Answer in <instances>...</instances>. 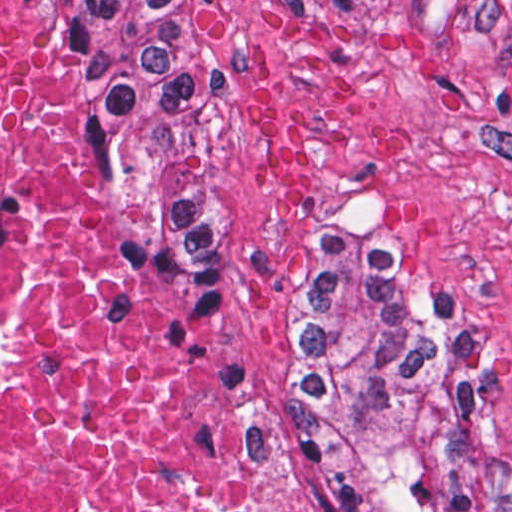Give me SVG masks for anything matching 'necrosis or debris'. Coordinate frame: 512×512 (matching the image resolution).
<instances>
[{
  "label": "necrosis or debris",
  "instance_id": "4bbe7bcc",
  "mask_svg": "<svg viewBox=\"0 0 512 512\" xmlns=\"http://www.w3.org/2000/svg\"><path fill=\"white\" fill-rule=\"evenodd\" d=\"M0 512H293L119 255L75 0H0Z\"/></svg>",
  "mask_w": 512,
  "mask_h": 512
}]
</instances>
